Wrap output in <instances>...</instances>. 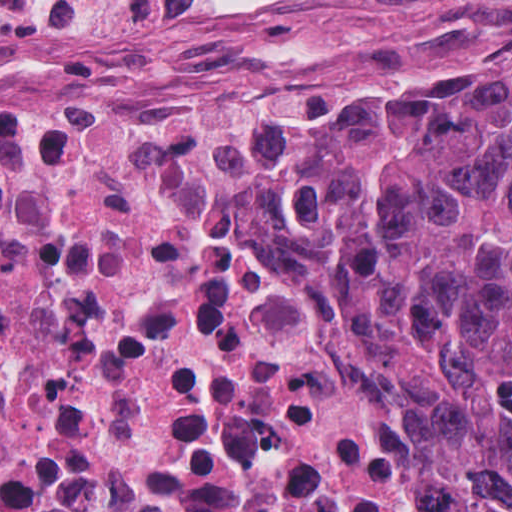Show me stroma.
<instances>
[{
  "label": "stroma",
  "mask_w": 512,
  "mask_h": 512,
  "mask_svg": "<svg viewBox=\"0 0 512 512\" xmlns=\"http://www.w3.org/2000/svg\"><path fill=\"white\" fill-rule=\"evenodd\" d=\"M226 2L231 14L210 25L122 40L70 62L0 69V112L218 105L268 130L271 119L375 75L512 64V0ZM410 412L420 456L458 512L441 456Z\"/></svg>",
  "instance_id": "35a3bbf8"
}]
</instances>
